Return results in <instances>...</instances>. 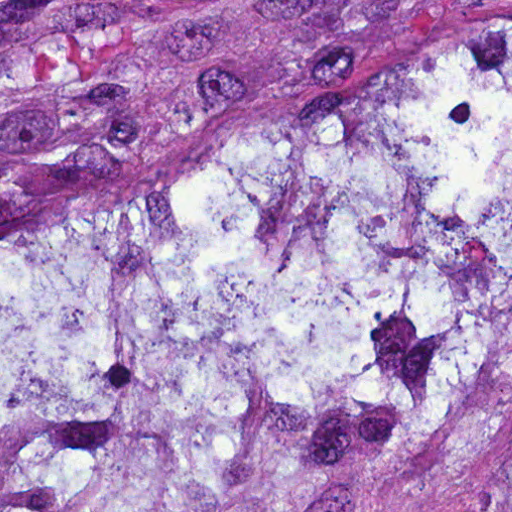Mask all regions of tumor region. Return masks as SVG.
Wrapping results in <instances>:
<instances>
[{"mask_svg": "<svg viewBox=\"0 0 512 512\" xmlns=\"http://www.w3.org/2000/svg\"><path fill=\"white\" fill-rule=\"evenodd\" d=\"M0 512H512V0H0Z\"/></svg>", "mask_w": 512, "mask_h": 512, "instance_id": "obj_1", "label": "tumor region"}]
</instances>
